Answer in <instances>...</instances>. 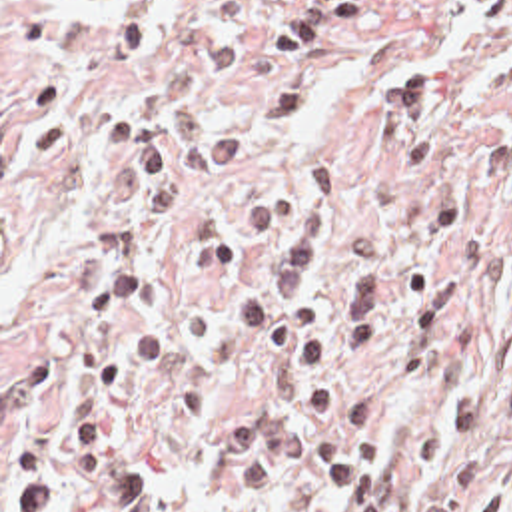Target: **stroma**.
Segmentation results:
<instances>
[{
	"label": "stroma",
	"instance_id": "35a3bbf8",
	"mask_svg": "<svg viewBox=\"0 0 512 512\" xmlns=\"http://www.w3.org/2000/svg\"><path fill=\"white\" fill-rule=\"evenodd\" d=\"M485 0H0V512H343L303 355L236 329L282 237L238 207L329 155L313 301L349 243L391 299L461 285L451 357L359 353L399 512L481 462L512 510V19Z\"/></svg>",
	"mask_w": 512,
	"mask_h": 512
}]
</instances>
